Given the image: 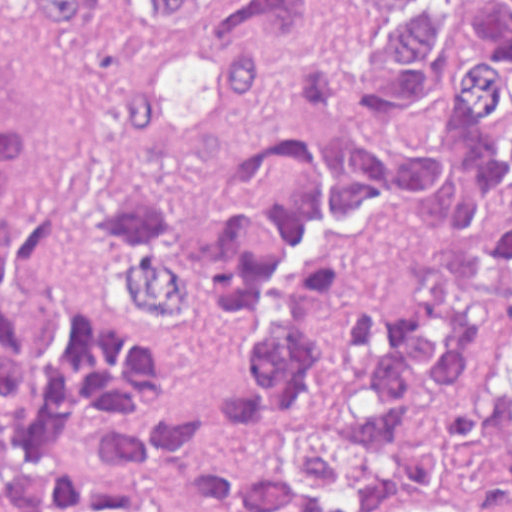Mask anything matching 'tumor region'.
<instances>
[{"instance_id": "1", "label": "tumor region", "mask_w": 512, "mask_h": 512, "mask_svg": "<svg viewBox=\"0 0 512 512\" xmlns=\"http://www.w3.org/2000/svg\"><path fill=\"white\" fill-rule=\"evenodd\" d=\"M118 4L197 45L123 78L131 140L207 130L276 60L298 97L368 122L284 131L212 213L170 208L133 173L107 180L130 294L211 310L244 341L211 396L127 406L167 373L165 352L91 294L75 214L5 207L26 131L0 89V512H181L79 457L98 419L107 456L217 507L386 512L463 472L512 497V353L481 401L416 431L462 397L476 337L512 295V0H37L68 40Z\"/></svg>"}]
</instances>
